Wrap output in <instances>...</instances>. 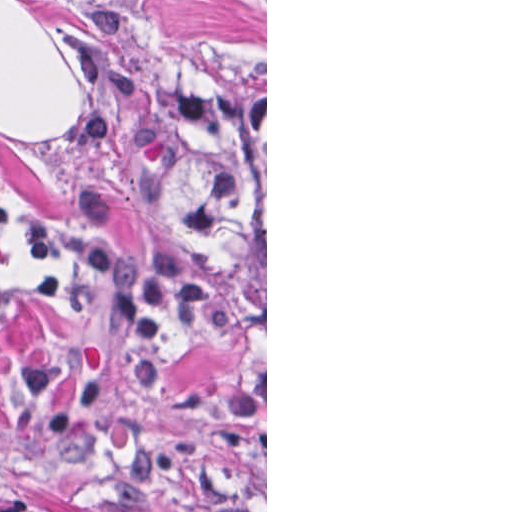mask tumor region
<instances>
[{"label":"tumor region","instance_id":"tumor-region-1","mask_svg":"<svg viewBox=\"0 0 512 512\" xmlns=\"http://www.w3.org/2000/svg\"><path fill=\"white\" fill-rule=\"evenodd\" d=\"M155 49L137 89L157 211L202 268L265 308V65ZM0 512H57L20 498Z\"/></svg>","mask_w":512,"mask_h":512}]
</instances>
